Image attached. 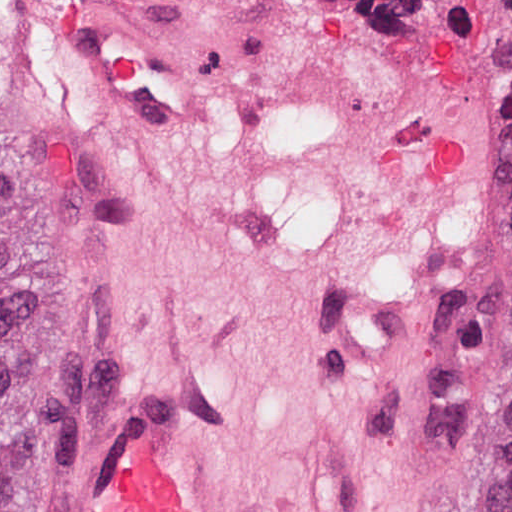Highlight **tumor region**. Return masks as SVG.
Here are the masks:
<instances>
[{"label":"tumor region","mask_w":512,"mask_h":512,"mask_svg":"<svg viewBox=\"0 0 512 512\" xmlns=\"http://www.w3.org/2000/svg\"><path fill=\"white\" fill-rule=\"evenodd\" d=\"M503 83V171L491 270L499 312L503 451L512 480V0L464 13ZM20 85L0 50V107ZM82 365V301L72 224L53 193L0 149V512H29Z\"/></svg>","instance_id":"obj_1"}]
</instances>
